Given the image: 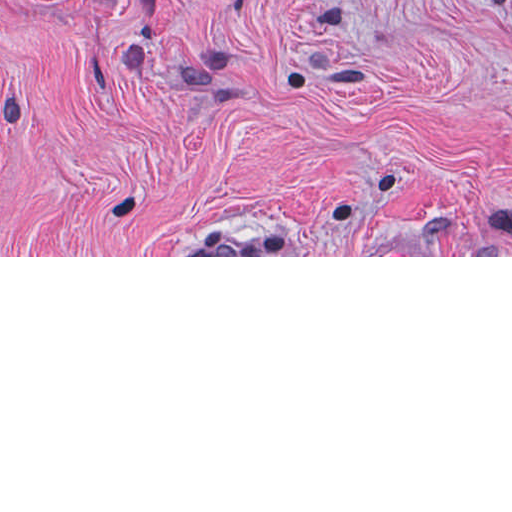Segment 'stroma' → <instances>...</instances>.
I'll return each instance as SVG.
<instances>
[{
    "instance_id": "obj_1",
    "label": "stroma",
    "mask_w": 512,
    "mask_h": 512,
    "mask_svg": "<svg viewBox=\"0 0 512 512\" xmlns=\"http://www.w3.org/2000/svg\"><path fill=\"white\" fill-rule=\"evenodd\" d=\"M0 257H512V0H0Z\"/></svg>"
}]
</instances>
